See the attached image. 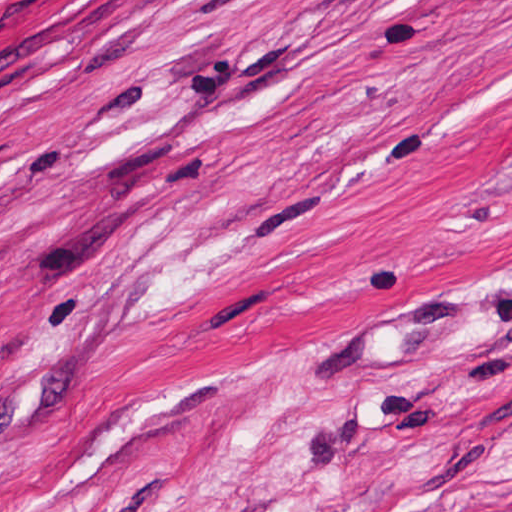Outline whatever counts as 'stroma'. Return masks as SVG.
Listing matches in <instances>:
<instances>
[{
    "instance_id": "stroma-1",
    "label": "stroma",
    "mask_w": 512,
    "mask_h": 512,
    "mask_svg": "<svg viewBox=\"0 0 512 512\" xmlns=\"http://www.w3.org/2000/svg\"><path fill=\"white\" fill-rule=\"evenodd\" d=\"M0 512H512V0H0Z\"/></svg>"
}]
</instances>
